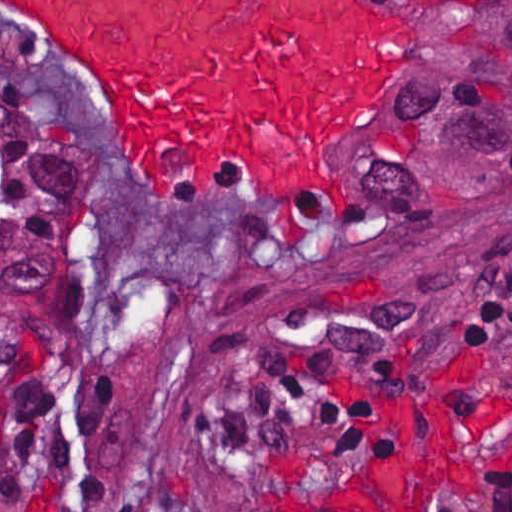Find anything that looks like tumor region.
<instances>
[{
	"mask_svg": "<svg viewBox=\"0 0 512 512\" xmlns=\"http://www.w3.org/2000/svg\"><path fill=\"white\" fill-rule=\"evenodd\" d=\"M430 30L369 140L373 245L413 249L512 194V0H419ZM382 136L381 230L370 150ZM95 150L0 90V325L48 328L86 262Z\"/></svg>",
	"mask_w": 512,
	"mask_h": 512,
	"instance_id": "tumor-region-1",
	"label": "tumor region"
}]
</instances>
